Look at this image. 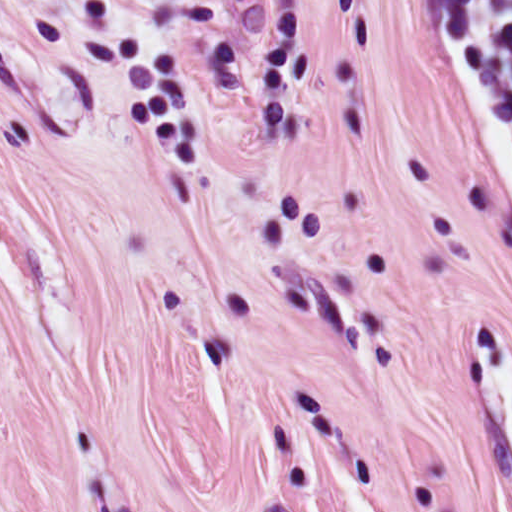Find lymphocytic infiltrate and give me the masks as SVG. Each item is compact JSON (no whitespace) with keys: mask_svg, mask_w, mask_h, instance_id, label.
<instances>
[{"mask_svg":"<svg viewBox=\"0 0 512 512\" xmlns=\"http://www.w3.org/2000/svg\"><path fill=\"white\" fill-rule=\"evenodd\" d=\"M448 63L512 198V0H444Z\"/></svg>","mask_w":512,"mask_h":512,"instance_id":"obj_1","label":"lymphocytic infiltrate"}]
</instances>
